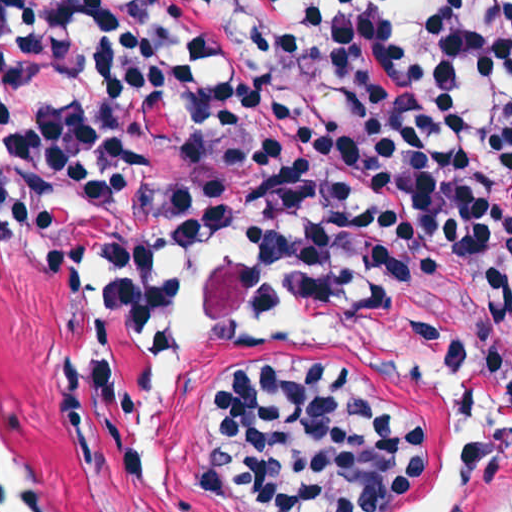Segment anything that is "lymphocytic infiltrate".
<instances>
[{
  "label": "lymphocytic infiltrate",
  "mask_w": 512,
  "mask_h": 512,
  "mask_svg": "<svg viewBox=\"0 0 512 512\" xmlns=\"http://www.w3.org/2000/svg\"><path fill=\"white\" fill-rule=\"evenodd\" d=\"M512 66V0H457L450 82ZM476 198H512V119L420 95L381 29L290 22L277 0H1V232L56 285L94 292L95 436L117 471L142 449L116 360L164 288L175 236L254 254L200 268H407ZM192 492L252 512H384L427 459V429L359 372L234 354ZM508 512H512L510 509Z\"/></svg>",
  "instance_id": "lymphocytic-infiltrate-1"
}]
</instances>
